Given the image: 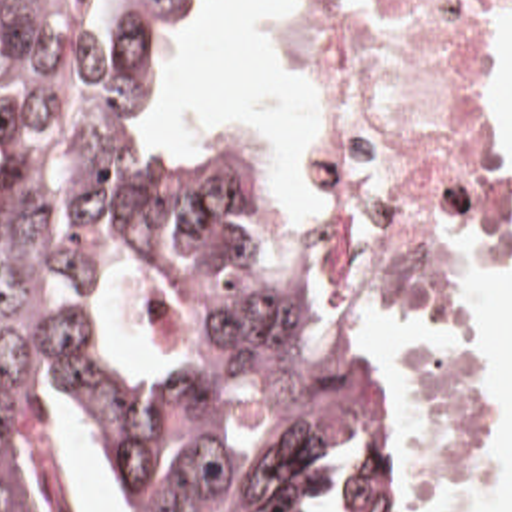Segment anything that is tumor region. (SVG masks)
Wrapping results in <instances>:
<instances>
[{
    "label": "tumor region",
    "mask_w": 512,
    "mask_h": 512,
    "mask_svg": "<svg viewBox=\"0 0 512 512\" xmlns=\"http://www.w3.org/2000/svg\"><path fill=\"white\" fill-rule=\"evenodd\" d=\"M211 3L0 0V512L57 488L37 383L117 450L149 512H295L361 438L377 470L349 512H395V371L323 325L275 171L179 147L145 119L157 21L185 33ZM131 259L205 307L191 359L119 367L101 353L95 303Z\"/></svg>",
    "instance_id": "e687c5a6"
}]
</instances>
